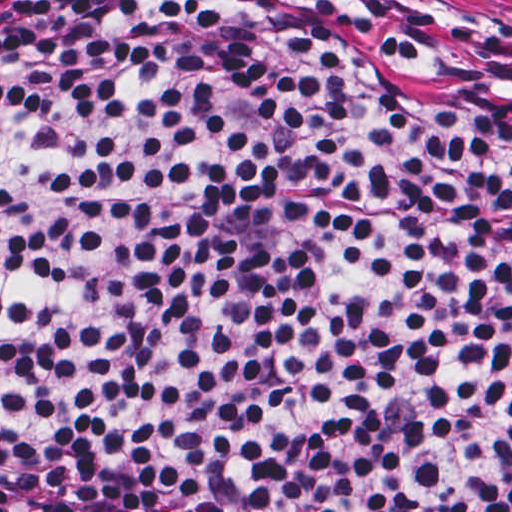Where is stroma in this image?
Returning <instances> with one entry per match:
<instances>
[{"mask_svg":"<svg viewBox=\"0 0 512 512\" xmlns=\"http://www.w3.org/2000/svg\"><path fill=\"white\" fill-rule=\"evenodd\" d=\"M512 21V0H456ZM0 512H30L15 499L0 495Z\"/></svg>","mask_w":512,"mask_h":512,"instance_id":"35a3bbf8","label":"stroma"}]
</instances>
